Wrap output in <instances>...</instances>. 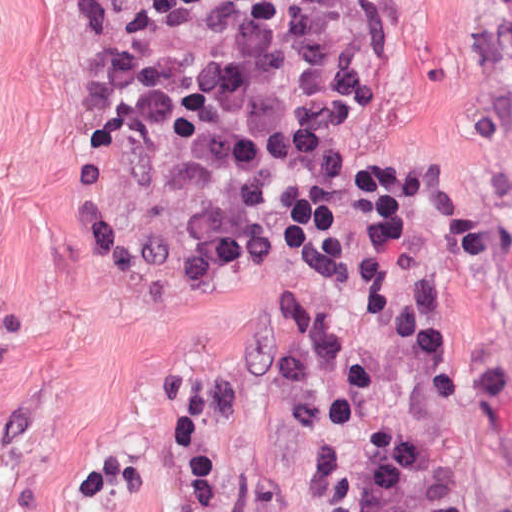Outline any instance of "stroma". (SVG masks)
Returning a JSON list of instances; mask_svg holds the SVG:
<instances>
[{"instance_id":"stroma-1","label":"stroma","mask_w":512,"mask_h":512,"mask_svg":"<svg viewBox=\"0 0 512 512\" xmlns=\"http://www.w3.org/2000/svg\"><path fill=\"white\" fill-rule=\"evenodd\" d=\"M100 0H0V512H367L303 289L215 143L137 130ZM388 90L303 123L396 192L438 335L512 372V0H401Z\"/></svg>"}]
</instances>
